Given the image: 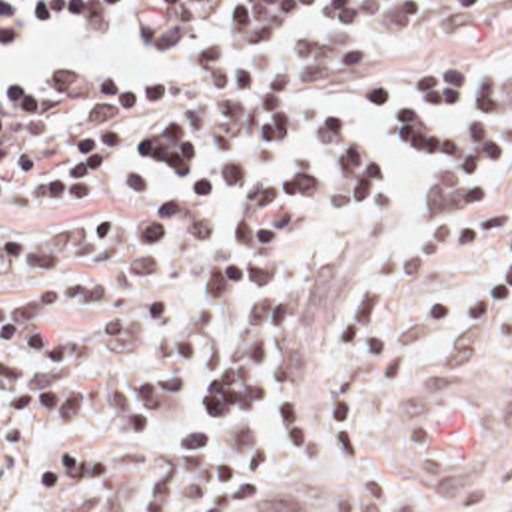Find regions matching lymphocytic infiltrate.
Segmentation results:
<instances>
[{
  "instance_id": "obj_1",
  "label": "lymphocytic infiltrate",
  "mask_w": 512,
  "mask_h": 512,
  "mask_svg": "<svg viewBox=\"0 0 512 512\" xmlns=\"http://www.w3.org/2000/svg\"><path fill=\"white\" fill-rule=\"evenodd\" d=\"M279 36L295 8L323 4L343 26L388 36L416 16V0H1L0 38L19 22L71 14L95 28L125 16L161 44L209 28ZM512 46V18L506 22ZM402 88L382 76L351 84L373 122L319 114L307 124V64L291 52L283 74L251 82L221 52L161 76H35L0 90V208L57 210L123 196L103 218H39L0 236V285L85 263L101 271L159 267L177 252L175 307L141 289L89 347L55 313L101 305L111 281L45 279L0 297V512L21 505L53 437L37 501L105 495L77 512H111L133 491L137 467L171 401L191 383L205 325L239 285L269 281L293 240L361 224L380 204L390 156L424 162V212L402 230L394 281L414 289L492 248L502 265L460 297L444 323L446 359L482 363L498 321H512V70L474 84L466 60L432 52ZM293 168L257 190L247 158ZM504 160L488 194L486 164ZM243 198L229 218L189 216ZM392 291L375 275L355 283L337 315L319 385L301 379L297 349L309 299L251 287L203 383L141 497L139 512H237L277 445L305 455L317 419L331 463L361 451L359 409L378 377L400 373L386 333ZM512 339V337H510Z\"/></svg>"
}]
</instances>
